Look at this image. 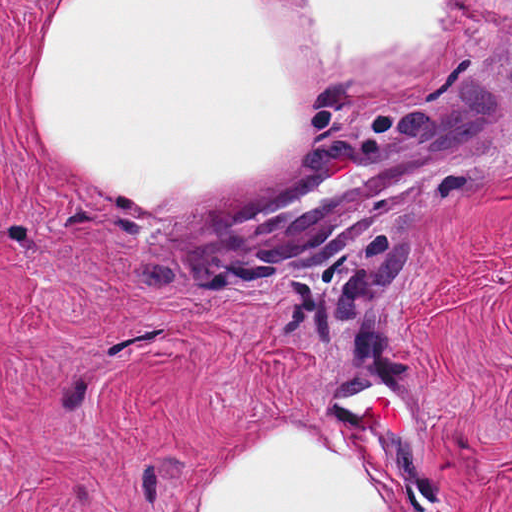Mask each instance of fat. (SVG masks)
I'll return each mask as SVG.
<instances>
[{
    "label": "fat",
    "mask_w": 512,
    "mask_h": 512,
    "mask_svg": "<svg viewBox=\"0 0 512 512\" xmlns=\"http://www.w3.org/2000/svg\"><path fill=\"white\" fill-rule=\"evenodd\" d=\"M458 27L459 1H72L36 124L107 200L222 208L286 179L332 108L424 84Z\"/></svg>",
    "instance_id": "1"
}]
</instances>
